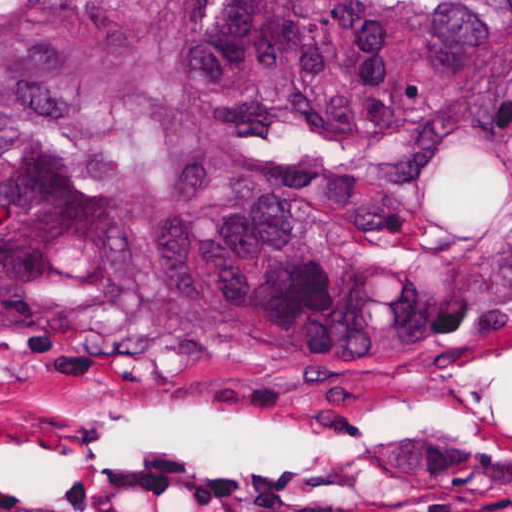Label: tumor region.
<instances>
[{
  "mask_svg": "<svg viewBox=\"0 0 512 512\" xmlns=\"http://www.w3.org/2000/svg\"><path fill=\"white\" fill-rule=\"evenodd\" d=\"M512 308V0H0V340L400 373Z\"/></svg>",
  "mask_w": 512,
  "mask_h": 512,
  "instance_id": "e687c5a6",
  "label": "tumor region"
}]
</instances>
